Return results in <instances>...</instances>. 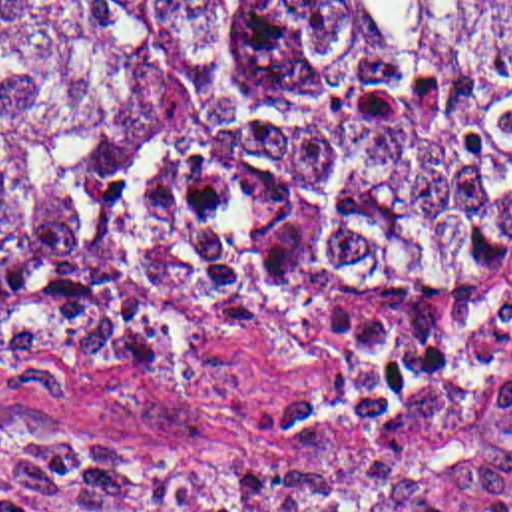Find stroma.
Instances as JSON below:
<instances>
[{"instance_id": "1", "label": "stroma", "mask_w": 512, "mask_h": 512, "mask_svg": "<svg viewBox=\"0 0 512 512\" xmlns=\"http://www.w3.org/2000/svg\"><path fill=\"white\" fill-rule=\"evenodd\" d=\"M451 284L473 286L479 306L512 304V261ZM439 290H400L384 298H308L266 334H238L179 368L111 388L0 380V418H35L97 448L165 456L125 454L137 460L226 468L280 482L312 511L328 512L290 486L278 450L246 424L242 410L306 406L346 378L342 356L320 334V312L426 300ZM465 512H512V494Z\"/></svg>"}]
</instances>
